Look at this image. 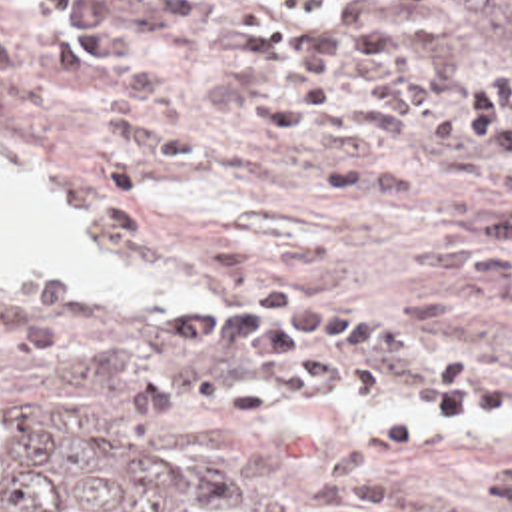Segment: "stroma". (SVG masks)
Returning a JSON list of instances; mask_svg holds the SVG:
<instances>
[{
    "mask_svg": "<svg viewBox=\"0 0 512 512\" xmlns=\"http://www.w3.org/2000/svg\"><path fill=\"white\" fill-rule=\"evenodd\" d=\"M264 1L218 0L236 15ZM310 13L324 0H278ZM378 27L430 77L512 87V55L450 51L424 0H370ZM0 27L25 67L0 85V172H27L63 228L149 276L143 306H57L0 286V380L59 396L83 430L206 512H250L334 444L410 404L336 402L276 424L186 408L145 426L131 382L158 366L234 370L232 354H182L145 338L170 302L228 304L256 282H296L314 298H360L386 318L474 358L512 348V310L450 290L412 248L502 192H430L352 202L314 184L350 160L288 141L244 97L196 23L154 19L103 75L77 79L39 51L37 0H0ZM512 460V424L462 420L412 450L372 458L386 502L362 512H492L490 468Z\"/></svg>",
    "mask_w": 512,
    "mask_h": 512,
    "instance_id": "stroma-1",
    "label": "stroma"
}]
</instances>
